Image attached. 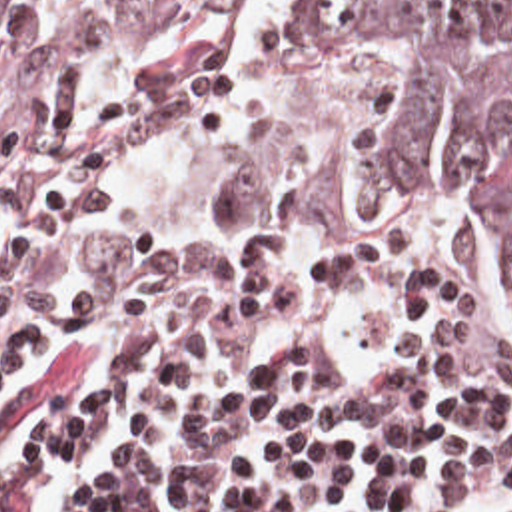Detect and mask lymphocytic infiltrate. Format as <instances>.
I'll return each instance as SVG.
<instances>
[{
  "label": "lymphocytic infiltrate",
  "instance_id": "obj_1",
  "mask_svg": "<svg viewBox=\"0 0 512 512\" xmlns=\"http://www.w3.org/2000/svg\"><path fill=\"white\" fill-rule=\"evenodd\" d=\"M266 113V85L202 73L160 93L64 85L0 161V337L68 333L128 303L356 295L400 317L483 325L491 241L434 203L390 199L352 243L256 253L144 245L132 185ZM102 387L60 399L0 473L28 512L52 467L116 429L122 451L74 512H462L512 481V355L422 323L222 303L116 325ZM36 351V349H34ZM34 351L0 367L2 393Z\"/></svg>",
  "mask_w": 512,
  "mask_h": 512
}]
</instances>
